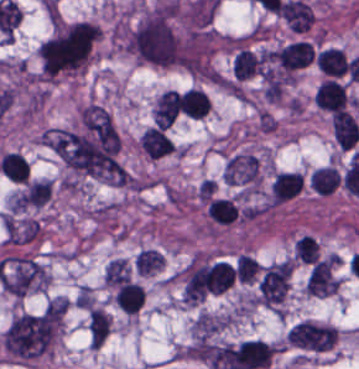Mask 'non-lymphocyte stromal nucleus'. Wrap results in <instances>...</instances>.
<instances>
[{
	"instance_id": "1",
	"label": "non-lymphocyte stromal nucleus",
	"mask_w": 359,
	"mask_h": 369,
	"mask_svg": "<svg viewBox=\"0 0 359 369\" xmlns=\"http://www.w3.org/2000/svg\"><path fill=\"white\" fill-rule=\"evenodd\" d=\"M336 336L335 327L308 319L293 324L285 340L289 348L307 356L333 347Z\"/></svg>"
},
{
	"instance_id": "6",
	"label": "non-lymphocyte stromal nucleus",
	"mask_w": 359,
	"mask_h": 369,
	"mask_svg": "<svg viewBox=\"0 0 359 369\" xmlns=\"http://www.w3.org/2000/svg\"><path fill=\"white\" fill-rule=\"evenodd\" d=\"M347 100L344 86L334 78H326L316 88L314 101L328 111L341 109Z\"/></svg>"
},
{
	"instance_id": "12",
	"label": "non-lymphocyte stromal nucleus",
	"mask_w": 359,
	"mask_h": 369,
	"mask_svg": "<svg viewBox=\"0 0 359 369\" xmlns=\"http://www.w3.org/2000/svg\"><path fill=\"white\" fill-rule=\"evenodd\" d=\"M316 67L326 74L341 75L347 69L345 54L338 47H328L316 53Z\"/></svg>"
},
{
	"instance_id": "3",
	"label": "non-lymphocyte stromal nucleus",
	"mask_w": 359,
	"mask_h": 369,
	"mask_svg": "<svg viewBox=\"0 0 359 369\" xmlns=\"http://www.w3.org/2000/svg\"><path fill=\"white\" fill-rule=\"evenodd\" d=\"M228 182L259 185V160L250 152H237L225 163Z\"/></svg>"
},
{
	"instance_id": "7",
	"label": "non-lymphocyte stromal nucleus",
	"mask_w": 359,
	"mask_h": 369,
	"mask_svg": "<svg viewBox=\"0 0 359 369\" xmlns=\"http://www.w3.org/2000/svg\"><path fill=\"white\" fill-rule=\"evenodd\" d=\"M315 51L307 41H294L281 47L275 56L282 68L296 69L309 63Z\"/></svg>"
},
{
	"instance_id": "13",
	"label": "non-lymphocyte stromal nucleus",
	"mask_w": 359,
	"mask_h": 369,
	"mask_svg": "<svg viewBox=\"0 0 359 369\" xmlns=\"http://www.w3.org/2000/svg\"><path fill=\"white\" fill-rule=\"evenodd\" d=\"M88 328L92 344H102L110 329V315L97 306H89Z\"/></svg>"
},
{
	"instance_id": "4",
	"label": "non-lymphocyte stromal nucleus",
	"mask_w": 359,
	"mask_h": 369,
	"mask_svg": "<svg viewBox=\"0 0 359 369\" xmlns=\"http://www.w3.org/2000/svg\"><path fill=\"white\" fill-rule=\"evenodd\" d=\"M263 68L262 52L249 46L233 49L231 73L235 78L247 80L260 74Z\"/></svg>"
},
{
	"instance_id": "5",
	"label": "non-lymphocyte stromal nucleus",
	"mask_w": 359,
	"mask_h": 369,
	"mask_svg": "<svg viewBox=\"0 0 359 369\" xmlns=\"http://www.w3.org/2000/svg\"><path fill=\"white\" fill-rule=\"evenodd\" d=\"M331 131L345 151L355 146L359 138L357 121L346 109H339L331 115Z\"/></svg>"
},
{
	"instance_id": "10",
	"label": "non-lymphocyte stromal nucleus",
	"mask_w": 359,
	"mask_h": 369,
	"mask_svg": "<svg viewBox=\"0 0 359 369\" xmlns=\"http://www.w3.org/2000/svg\"><path fill=\"white\" fill-rule=\"evenodd\" d=\"M179 96L182 111L189 117L201 119L211 106L208 96L197 87H190Z\"/></svg>"
},
{
	"instance_id": "2",
	"label": "non-lymphocyte stromal nucleus",
	"mask_w": 359,
	"mask_h": 369,
	"mask_svg": "<svg viewBox=\"0 0 359 369\" xmlns=\"http://www.w3.org/2000/svg\"><path fill=\"white\" fill-rule=\"evenodd\" d=\"M340 283V260L329 254L310 268L305 282L306 294L327 296L337 290Z\"/></svg>"
},
{
	"instance_id": "8",
	"label": "non-lymphocyte stromal nucleus",
	"mask_w": 359,
	"mask_h": 369,
	"mask_svg": "<svg viewBox=\"0 0 359 369\" xmlns=\"http://www.w3.org/2000/svg\"><path fill=\"white\" fill-rule=\"evenodd\" d=\"M180 106V97L174 89L162 92L153 109L156 126L168 128L174 121Z\"/></svg>"
},
{
	"instance_id": "15",
	"label": "non-lymphocyte stromal nucleus",
	"mask_w": 359,
	"mask_h": 369,
	"mask_svg": "<svg viewBox=\"0 0 359 369\" xmlns=\"http://www.w3.org/2000/svg\"><path fill=\"white\" fill-rule=\"evenodd\" d=\"M130 277V269L125 259H112L104 270L103 281L107 286H117Z\"/></svg>"
},
{
	"instance_id": "11",
	"label": "non-lymphocyte stromal nucleus",
	"mask_w": 359,
	"mask_h": 369,
	"mask_svg": "<svg viewBox=\"0 0 359 369\" xmlns=\"http://www.w3.org/2000/svg\"><path fill=\"white\" fill-rule=\"evenodd\" d=\"M340 179V175L332 165L315 167L309 175L313 191L324 196L335 191Z\"/></svg>"
},
{
	"instance_id": "14",
	"label": "non-lymphocyte stromal nucleus",
	"mask_w": 359,
	"mask_h": 369,
	"mask_svg": "<svg viewBox=\"0 0 359 369\" xmlns=\"http://www.w3.org/2000/svg\"><path fill=\"white\" fill-rule=\"evenodd\" d=\"M164 255L154 248H140L134 257L135 269L142 274H150L161 269Z\"/></svg>"
},
{
	"instance_id": "9",
	"label": "non-lymphocyte stromal nucleus",
	"mask_w": 359,
	"mask_h": 369,
	"mask_svg": "<svg viewBox=\"0 0 359 369\" xmlns=\"http://www.w3.org/2000/svg\"><path fill=\"white\" fill-rule=\"evenodd\" d=\"M139 143L150 157H159L174 150L172 140L156 125H149L142 133Z\"/></svg>"
}]
</instances>
